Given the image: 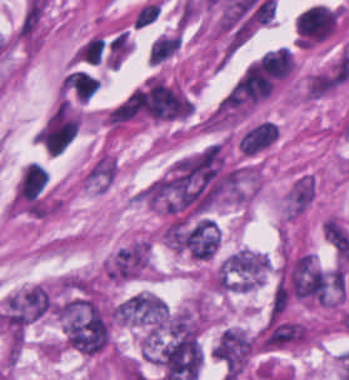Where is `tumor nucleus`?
Wrapping results in <instances>:
<instances>
[{"label": "tumor nucleus", "mask_w": 349, "mask_h": 380, "mask_svg": "<svg viewBox=\"0 0 349 380\" xmlns=\"http://www.w3.org/2000/svg\"><path fill=\"white\" fill-rule=\"evenodd\" d=\"M168 306L155 294L138 291L122 299L119 323L151 337H159L166 329Z\"/></svg>", "instance_id": "tumor-nucleus-1"}, {"label": "tumor nucleus", "mask_w": 349, "mask_h": 380, "mask_svg": "<svg viewBox=\"0 0 349 380\" xmlns=\"http://www.w3.org/2000/svg\"><path fill=\"white\" fill-rule=\"evenodd\" d=\"M269 271L267 257L257 251L241 249L222 260L221 290L248 292L258 287Z\"/></svg>", "instance_id": "tumor-nucleus-2"}, {"label": "tumor nucleus", "mask_w": 349, "mask_h": 380, "mask_svg": "<svg viewBox=\"0 0 349 380\" xmlns=\"http://www.w3.org/2000/svg\"><path fill=\"white\" fill-rule=\"evenodd\" d=\"M256 352L253 336L239 327H226L213 347V355L226 380H239Z\"/></svg>", "instance_id": "tumor-nucleus-3"}]
</instances>
